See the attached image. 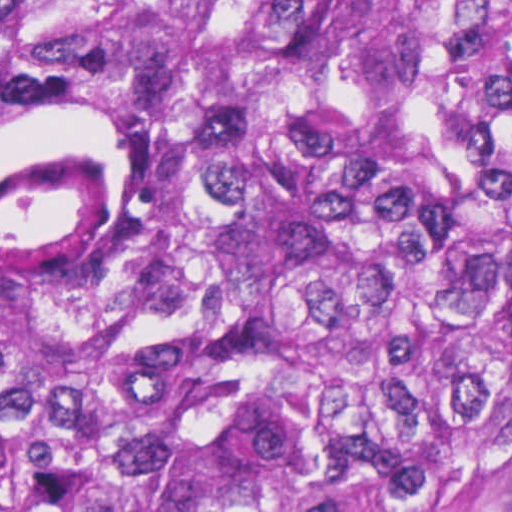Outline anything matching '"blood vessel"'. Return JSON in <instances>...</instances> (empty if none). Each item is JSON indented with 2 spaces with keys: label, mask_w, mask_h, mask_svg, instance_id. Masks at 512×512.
I'll return each mask as SVG.
<instances>
[{
  "label": "blood vessel",
  "mask_w": 512,
  "mask_h": 512,
  "mask_svg": "<svg viewBox=\"0 0 512 512\" xmlns=\"http://www.w3.org/2000/svg\"><path fill=\"white\" fill-rule=\"evenodd\" d=\"M122 228L120 177L98 152L45 143L0 163V272L83 280Z\"/></svg>",
  "instance_id": "1"
}]
</instances>
